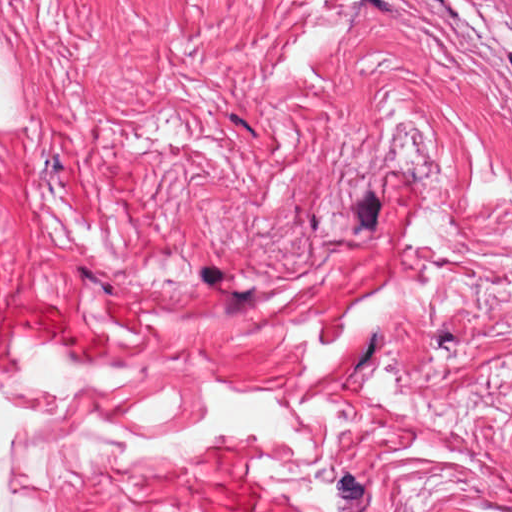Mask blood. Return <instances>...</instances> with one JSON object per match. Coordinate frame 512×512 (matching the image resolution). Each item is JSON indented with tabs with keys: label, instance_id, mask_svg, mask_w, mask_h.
Instances as JSON below:
<instances>
[{
	"label": "blood",
	"instance_id": "1a1defca",
	"mask_svg": "<svg viewBox=\"0 0 512 512\" xmlns=\"http://www.w3.org/2000/svg\"><path fill=\"white\" fill-rule=\"evenodd\" d=\"M77 322V317L29 292L0 297V374L57 342Z\"/></svg>",
	"mask_w": 512,
	"mask_h": 512
}]
</instances>
